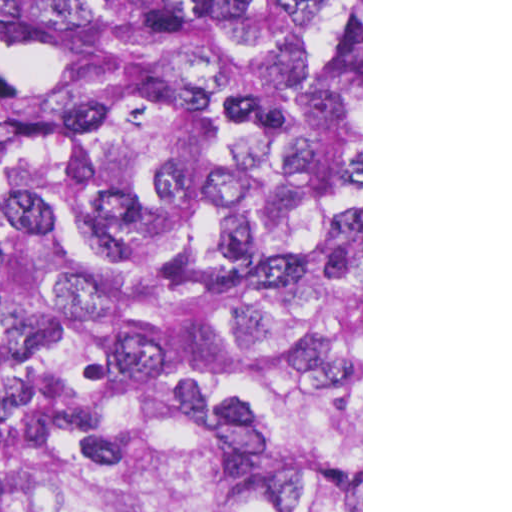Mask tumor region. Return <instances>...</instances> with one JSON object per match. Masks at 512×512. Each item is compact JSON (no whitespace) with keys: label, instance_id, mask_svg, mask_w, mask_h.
<instances>
[{"label":"tumor region","instance_id":"tumor-region-1","mask_svg":"<svg viewBox=\"0 0 512 512\" xmlns=\"http://www.w3.org/2000/svg\"><path fill=\"white\" fill-rule=\"evenodd\" d=\"M0 0V512H361V19Z\"/></svg>","mask_w":512,"mask_h":512}]
</instances>
